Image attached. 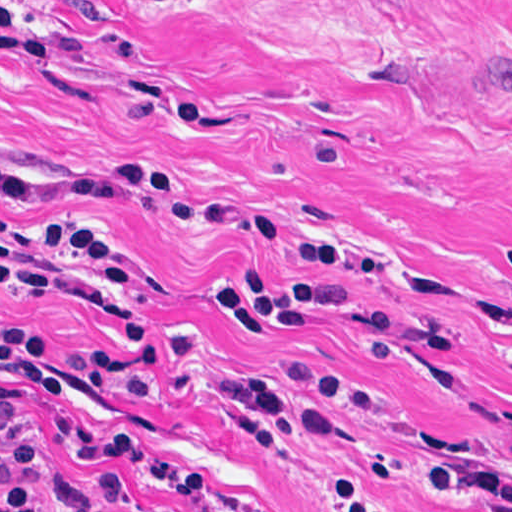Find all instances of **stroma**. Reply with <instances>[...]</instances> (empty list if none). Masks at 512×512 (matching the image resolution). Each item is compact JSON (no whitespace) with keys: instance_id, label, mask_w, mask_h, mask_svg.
<instances>
[{"instance_id":"obj_1","label":"stroma","mask_w":512,"mask_h":512,"mask_svg":"<svg viewBox=\"0 0 512 512\" xmlns=\"http://www.w3.org/2000/svg\"><path fill=\"white\" fill-rule=\"evenodd\" d=\"M502 10L512 0H0V159L11 171L157 172L238 216L371 250L406 283L194 229L165 195L0 202L12 286L0 284V326L57 346L43 370L62 382L27 421L0 414V444L31 470L36 507L512 512L499 497L463 496L416 455L512 469ZM52 217L114 241L135 290L19 232ZM227 268L339 281L353 304L310 331L238 338L214 287ZM125 334L137 340L125 346ZM81 351H125L142 398L100 389ZM96 428L140 433L165 460L83 452L53 506L43 474Z\"/></svg>"}]
</instances>
